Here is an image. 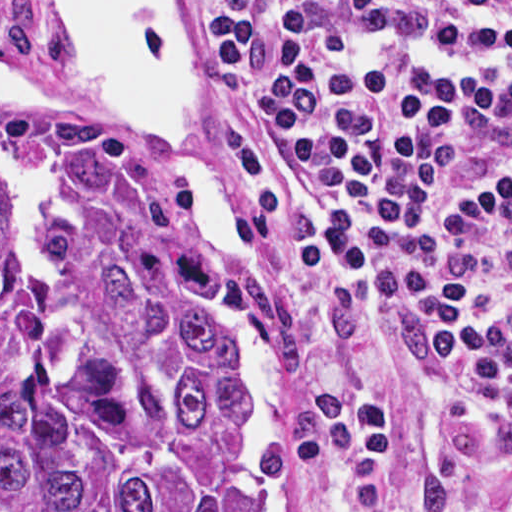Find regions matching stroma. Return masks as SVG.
Segmentation results:
<instances>
[{"mask_svg": "<svg viewBox=\"0 0 512 512\" xmlns=\"http://www.w3.org/2000/svg\"><path fill=\"white\" fill-rule=\"evenodd\" d=\"M194 45L197 100L243 233L255 287L270 307L283 446L278 512H372L369 457L329 391L339 290L289 223L264 134L224 79L200 0H172ZM57 0H0V68L55 81ZM0 93V512H1ZM16 105V104H15ZM124 172L200 237L193 186L149 130L97 115L30 112ZM201 238V237H200ZM395 512H512V432L466 387L431 377L393 428Z\"/></svg>", "mask_w": 512, "mask_h": 512, "instance_id": "35a3bbf8", "label": "stroma"}]
</instances>
